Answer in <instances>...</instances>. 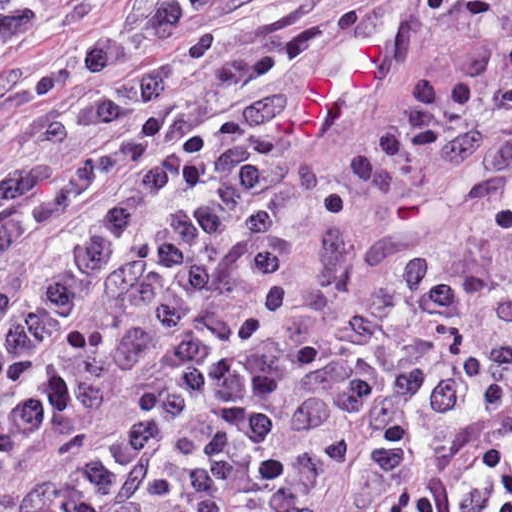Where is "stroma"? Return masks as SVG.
<instances>
[{
  "label": "stroma",
  "mask_w": 512,
  "mask_h": 512,
  "mask_svg": "<svg viewBox=\"0 0 512 512\" xmlns=\"http://www.w3.org/2000/svg\"><path fill=\"white\" fill-rule=\"evenodd\" d=\"M57 13L52 30L15 51L0 67V151L21 166L68 167L92 158L96 145L42 143L38 125L61 113L113 99L186 62L198 51L273 27L295 14L322 4L319 12L291 22L266 38L279 41L350 12L362 15V27L337 43L294 65L283 77L286 95L300 92L317 76L348 82L363 46L387 42L403 26L413 30L403 71L346 123L321 141L302 147L288 158L293 169L330 184L349 172L365 138L388 113L414 71L453 81L462 69L466 46L477 19L447 16L418 9L415 0H290L258 16L196 43L162 53L116 73L103 76L70 92L40 96L36 85L87 50L158 12L174 0H45ZM120 181L111 175L80 202L58 226L39 232L8 257L0 258V282L28 273L41 265L58 242L74 233L100 193ZM506 263L512 267V231L507 236ZM389 479L358 478L346 462L328 477L316 500V512H377L394 498Z\"/></svg>",
  "instance_id": "35a3bbf8"
}]
</instances>
